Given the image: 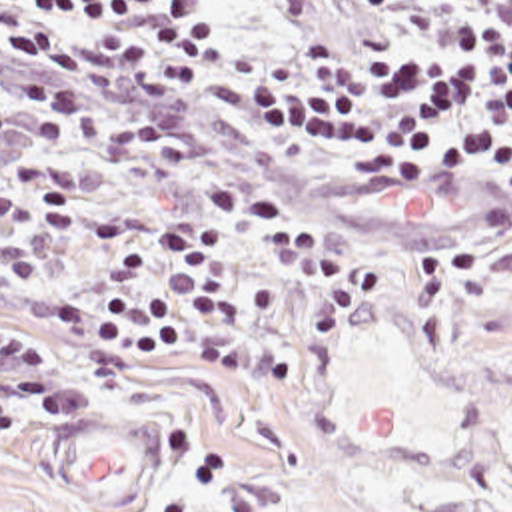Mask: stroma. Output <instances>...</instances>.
Instances as JSON below:
<instances>
[{
	"label": "stroma",
	"mask_w": 512,
	"mask_h": 512,
	"mask_svg": "<svg viewBox=\"0 0 512 512\" xmlns=\"http://www.w3.org/2000/svg\"><path fill=\"white\" fill-rule=\"evenodd\" d=\"M382 22L407 24L405 0H238L250 56ZM14 82L0 74V106L34 114L8 90ZM80 88L94 112L110 100L118 116L176 126L190 158L136 162L76 134L0 136V190L16 160L54 162L76 182V218L50 262L28 286L0 290V320L54 345L76 407L60 423L26 417L0 449V512L459 511L423 162L421 178L392 172L348 186L274 136L180 96L126 102L114 86ZM212 184L258 188L318 214L374 254L376 284L316 347L296 389L232 383L202 363V340L218 330L290 334L318 280L228 230L224 318L150 383L80 391L76 353L48 332V312L60 290L92 276L88 214L126 200L200 208Z\"/></svg>",
	"instance_id": "stroma-1"
}]
</instances>
